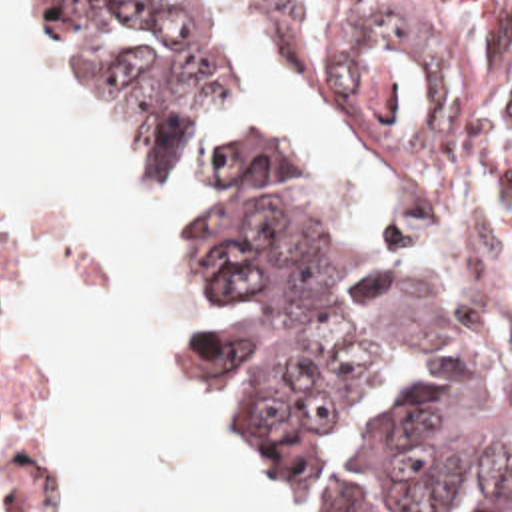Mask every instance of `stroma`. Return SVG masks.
<instances>
[{
  "label": "stroma",
  "instance_id": "obj_1",
  "mask_svg": "<svg viewBox=\"0 0 512 512\" xmlns=\"http://www.w3.org/2000/svg\"><path fill=\"white\" fill-rule=\"evenodd\" d=\"M304 56L308 58L320 88L330 104V110L334 114V120L346 140V144L350 146V150L354 152L356 160L360 162V166L376 172L382 176V172L376 168V164L370 160V156L364 152V148L360 146V142L354 138V134L350 132V128L346 126V122L342 120V116L338 114V110L334 108V104L328 98V90H326V78H324V64H322V56H318L316 52H312L308 46H304L302 42H298ZM37 48L43 54V58L47 60L49 68L53 70V62L49 56V50L43 42V38L37 32ZM55 74V70H53ZM65 90V88H63ZM69 96V94H67ZM71 98V96H69ZM73 102V100H71ZM75 104V102H73ZM77 106V104H75ZM79 110V108H77ZM81 112V110H79ZM388 182V180H386ZM390 184V182H388ZM392 192L396 194V218L398 222L404 226V230L432 256V260L442 268V272L448 276L460 304L476 318V322L492 336L502 360L506 362V366L512 370V318L506 310V306L502 304L496 288L490 284V280L480 272V268L472 262V258L464 252V248L454 240V236L446 230V226L442 222H438L436 218L428 216L426 212H422L420 208L412 206L392 184H390ZM0 375L5 379L13 381L15 385L21 387L25 403H27V411L33 423V431H35V441H37V451H39V459L41 465L45 469L47 481H49V491L39 499L41 501V511H43V503L47 501V497L53 491V483H51V427H53V397L45 385V381L35 374L29 366L13 360L1 340V330H3V318L13 302V298L17 296L19 288L25 282V230L17 218V214L3 202L0 198ZM176 322V320H174ZM176 332H178V340H180V348L186 360V366L190 370V374L194 377L196 383V374H194V366H192V358L188 354L186 342L182 338V328L180 322H176ZM198 389V383H196ZM200 395V391H198ZM202 401V395H200ZM204 407V401H202ZM206 411V407H204ZM206 417L218 437L224 439L222 431L216 427V423L210 419L208 411ZM0 512H23L21 505L17 503V499L13 497L11 489L7 487V483L3 481L0 475Z\"/></svg>",
  "mask_w": 512,
  "mask_h": 512
}]
</instances>
